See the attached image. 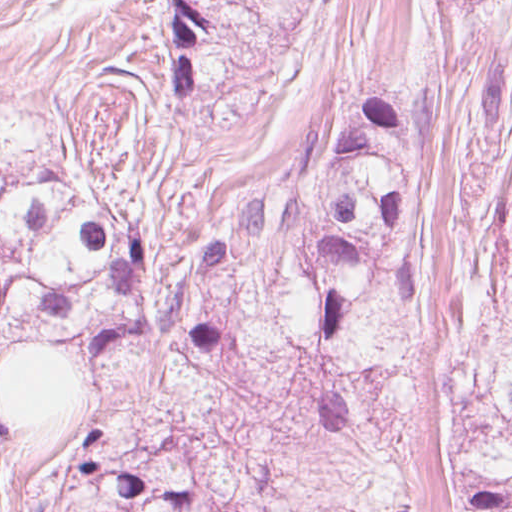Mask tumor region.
<instances>
[{"mask_svg":"<svg viewBox=\"0 0 512 512\" xmlns=\"http://www.w3.org/2000/svg\"><path fill=\"white\" fill-rule=\"evenodd\" d=\"M473 1V0H434ZM424 120L408 103L341 106L316 161L212 215L168 311L193 372L301 362L314 420L364 428L410 403L428 309L419 269ZM158 273L152 232L103 185L0 167V356L48 334L83 362L139 339ZM449 512H512V232L502 289L449 389ZM15 435L0 421V448ZM27 512H244L175 441L83 430Z\"/></svg>","mask_w":512,"mask_h":512,"instance_id":"1","label":"tumor region"}]
</instances>
